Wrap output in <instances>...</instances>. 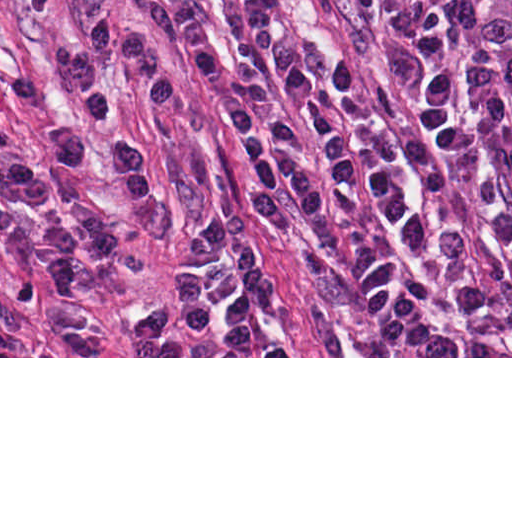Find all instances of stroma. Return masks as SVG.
I'll return each instance as SVG.
<instances>
[{"label": "stroma", "mask_w": 512, "mask_h": 512, "mask_svg": "<svg viewBox=\"0 0 512 512\" xmlns=\"http://www.w3.org/2000/svg\"><path fill=\"white\" fill-rule=\"evenodd\" d=\"M146 36L172 73V103L146 102L125 69L111 65L108 83L149 169L151 199L134 205L110 156L73 166L55 151L50 131L74 123L102 141L105 131L79 103L66 74L68 48L90 18ZM415 12L398 0H291L267 51H253L235 0H0V58L32 76L36 104L0 86V124L17 134L45 180L42 203L2 204L33 218L97 213L114 221V249L87 266L84 286L60 293L27 276L0 245V313L14 327V348L0 358H512V356H363L332 287L344 245L382 202L346 196L329 234L304 224L273 232L258 219L255 182L224 115L226 89L190 56L185 37L205 39L225 61L247 56L270 67L290 58L327 77L345 58L373 91L403 137L400 178L420 149V128L435 91L412 39ZM225 213L282 283L280 308L259 311L254 339L225 347L214 327L185 338L184 356H148L153 345L135 320L159 292L175 301L185 245Z\"/></svg>", "instance_id": "stroma-1"}]
</instances>
